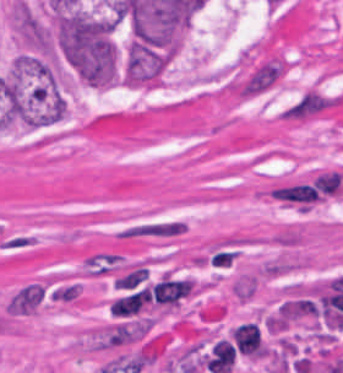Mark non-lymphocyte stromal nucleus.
I'll return each mask as SVG.
<instances>
[{
	"label": "non-lymphocyte stromal nucleus",
	"mask_w": 343,
	"mask_h": 373,
	"mask_svg": "<svg viewBox=\"0 0 343 373\" xmlns=\"http://www.w3.org/2000/svg\"><path fill=\"white\" fill-rule=\"evenodd\" d=\"M52 291L48 278L27 280L17 286L5 302L6 314L26 316L37 312Z\"/></svg>",
	"instance_id": "dd21d789"
},
{
	"label": "non-lymphocyte stromal nucleus",
	"mask_w": 343,
	"mask_h": 373,
	"mask_svg": "<svg viewBox=\"0 0 343 373\" xmlns=\"http://www.w3.org/2000/svg\"><path fill=\"white\" fill-rule=\"evenodd\" d=\"M188 225L179 219L140 221L117 231L119 239H172L187 231Z\"/></svg>",
	"instance_id": "a72fc3eb"
},
{
	"label": "non-lymphocyte stromal nucleus",
	"mask_w": 343,
	"mask_h": 373,
	"mask_svg": "<svg viewBox=\"0 0 343 373\" xmlns=\"http://www.w3.org/2000/svg\"><path fill=\"white\" fill-rule=\"evenodd\" d=\"M269 194L279 200L295 201L304 204H312L323 200V197L315 187L308 183L279 185L269 190Z\"/></svg>",
	"instance_id": "3746e769"
},
{
	"label": "non-lymphocyte stromal nucleus",
	"mask_w": 343,
	"mask_h": 373,
	"mask_svg": "<svg viewBox=\"0 0 343 373\" xmlns=\"http://www.w3.org/2000/svg\"><path fill=\"white\" fill-rule=\"evenodd\" d=\"M323 195H337L343 193V172L326 171L313 182Z\"/></svg>",
	"instance_id": "fc2b8d12"
}]
</instances>
